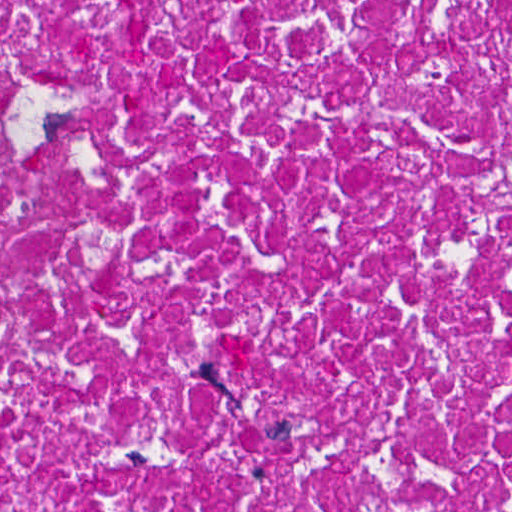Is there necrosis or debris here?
Masks as SVG:
<instances>
[{"instance_id":"4bbe7bcc","label":"necrosis or debris","mask_w":512,"mask_h":512,"mask_svg":"<svg viewBox=\"0 0 512 512\" xmlns=\"http://www.w3.org/2000/svg\"><path fill=\"white\" fill-rule=\"evenodd\" d=\"M0 512H512V0H0Z\"/></svg>"}]
</instances>
